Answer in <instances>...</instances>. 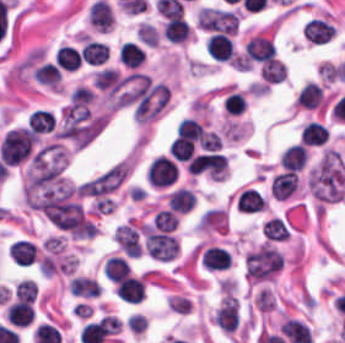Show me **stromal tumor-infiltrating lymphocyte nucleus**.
<instances>
[{
  "label": "stromal tumor-infiltrating lymphocyte nucleus",
  "mask_w": 345,
  "mask_h": 343,
  "mask_svg": "<svg viewBox=\"0 0 345 343\" xmlns=\"http://www.w3.org/2000/svg\"><path fill=\"white\" fill-rule=\"evenodd\" d=\"M146 176L152 187H166L176 181L178 170L173 160L159 155L149 165Z\"/></svg>",
  "instance_id": "obj_1"
},
{
  "label": "stromal tumor-infiltrating lymphocyte nucleus",
  "mask_w": 345,
  "mask_h": 343,
  "mask_svg": "<svg viewBox=\"0 0 345 343\" xmlns=\"http://www.w3.org/2000/svg\"><path fill=\"white\" fill-rule=\"evenodd\" d=\"M245 59L265 62L274 57L273 41L264 36H251L243 50Z\"/></svg>",
  "instance_id": "obj_2"
},
{
  "label": "stromal tumor-infiltrating lymphocyte nucleus",
  "mask_w": 345,
  "mask_h": 343,
  "mask_svg": "<svg viewBox=\"0 0 345 343\" xmlns=\"http://www.w3.org/2000/svg\"><path fill=\"white\" fill-rule=\"evenodd\" d=\"M205 48L208 54L218 61H226L235 55L231 38L220 32L209 34L205 42Z\"/></svg>",
  "instance_id": "obj_3"
},
{
  "label": "stromal tumor-infiltrating lymphocyte nucleus",
  "mask_w": 345,
  "mask_h": 343,
  "mask_svg": "<svg viewBox=\"0 0 345 343\" xmlns=\"http://www.w3.org/2000/svg\"><path fill=\"white\" fill-rule=\"evenodd\" d=\"M114 292L121 301L139 303L144 298V283L142 279L128 274L116 282Z\"/></svg>",
  "instance_id": "obj_4"
},
{
  "label": "stromal tumor-infiltrating lymphocyte nucleus",
  "mask_w": 345,
  "mask_h": 343,
  "mask_svg": "<svg viewBox=\"0 0 345 343\" xmlns=\"http://www.w3.org/2000/svg\"><path fill=\"white\" fill-rule=\"evenodd\" d=\"M302 31L308 41L319 44L333 37L335 26L318 17H311L306 21Z\"/></svg>",
  "instance_id": "obj_5"
},
{
  "label": "stromal tumor-infiltrating lymphocyte nucleus",
  "mask_w": 345,
  "mask_h": 343,
  "mask_svg": "<svg viewBox=\"0 0 345 343\" xmlns=\"http://www.w3.org/2000/svg\"><path fill=\"white\" fill-rule=\"evenodd\" d=\"M5 314L7 320L16 327H26L34 318L31 304L25 301L10 302Z\"/></svg>",
  "instance_id": "obj_6"
},
{
  "label": "stromal tumor-infiltrating lymphocyte nucleus",
  "mask_w": 345,
  "mask_h": 343,
  "mask_svg": "<svg viewBox=\"0 0 345 343\" xmlns=\"http://www.w3.org/2000/svg\"><path fill=\"white\" fill-rule=\"evenodd\" d=\"M202 264L209 270H222L230 267L231 254L226 248L208 246L202 255Z\"/></svg>",
  "instance_id": "obj_7"
},
{
  "label": "stromal tumor-infiltrating lymphocyte nucleus",
  "mask_w": 345,
  "mask_h": 343,
  "mask_svg": "<svg viewBox=\"0 0 345 343\" xmlns=\"http://www.w3.org/2000/svg\"><path fill=\"white\" fill-rule=\"evenodd\" d=\"M327 126L317 119H310L302 128L300 137L302 144L322 145L328 138Z\"/></svg>",
  "instance_id": "obj_8"
},
{
  "label": "stromal tumor-infiltrating lymphocyte nucleus",
  "mask_w": 345,
  "mask_h": 343,
  "mask_svg": "<svg viewBox=\"0 0 345 343\" xmlns=\"http://www.w3.org/2000/svg\"><path fill=\"white\" fill-rule=\"evenodd\" d=\"M322 102L321 85L312 81H305L298 94L295 97L294 103L301 108H314L319 106Z\"/></svg>",
  "instance_id": "obj_9"
},
{
  "label": "stromal tumor-infiltrating lymphocyte nucleus",
  "mask_w": 345,
  "mask_h": 343,
  "mask_svg": "<svg viewBox=\"0 0 345 343\" xmlns=\"http://www.w3.org/2000/svg\"><path fill=\"white\" fill-rule=\"evenodd\" d=\"M92 80L98 90L113 93L119 90L124 79L118 70L107 67L94 73Z\"/></svg>",
  "instance_id": "obj_10"
},
{
  "label": "stromal tumor-infiltrating lymphocyte nucleus",
  "mask_w": 345,
  "mask_h": 343,
  "mask_svg": "<svg viewBox=\"0 0 345 343\" xmlns=\"http://www.w3.org/2000/svg\"><path fill=\"white\" fill-rule=\"evenodd\" d=\"M81 59L90 65H101L108 57L106 43L87 40L80 49Z\"/></svg>",
  "instance_id": "obj_11"
},
{
  "label": "stromal tumor-infiltrating lymphocyte nucleus",
  "mask_w": 345,
  "mask_h": 343,
  "mask_svg": "<svg viewBox=\"0 0 345 343\" xmlns=\"http://www.w3.org/2000/svg\"><path fill=\"white\" fill-rule=\"evenodd\" d=\"M8 254L17 264H31L36 256V248L25 239H17L10 242Z\"/></svg>",
  "instance_id": "obj_12"
},
{
  "label": "stromal tumor-infiltrating lymphocyte nucleus",
  "mask_w": 345,
  "mask_h": 343,
  "mask_svg": "<svg viewBox=\"0 0 345 343\" xmlns=\"http://www.w3.org/2000/svg\"><path fill=\"white\" fill-rule=\"evenodd\" d=\"M55 64L59 69L76 70L81 65L79 51L69 44H62L54 55Z\"/></svg>",
  "instance_id": "obj_13"
},
{
  "label": "stromal tumor-infiltrating lymphocyte nucleus",
  "mask_w": 345,
  "mask_h": 343,
  "mask_svg": "<svg viewBox=\"0 0 345 343\" xmlns=\"http://www.w3.org/2000/svg\"><path fill=\"white\" fill-rule=\"evenodd\" d=\"M305 158V145L301 143H294L284 150V152L280 156L279 163L280 166L286 167L291 170H301Z\"/></svg>",
  "instance_id": "obj_14"
},
{
  "label": "stromal tumor-infiltrating lymphocyte nucleus",
  "mask_w": 345,
  "mask_h": 343,
  "mask_svg": "<svg viewBox=\"0 0 345 343\" xmlns=\"http://www.w3.org/2000/svg\"><path fill=\"white\" fill-rule=\"evenodd\" d=\"M190 30L182 17H168L162 36L171 42H184Z\"/></svg>",
  "instance_id": "obj_15"
},
{
  "label": "stromal tumor-infiltrating lymphocyte nucleus",
  "mask_w": 345,
  "mask_h": 343,
  "mask_svg": "<svg viewBox=\"0 0 345 343\" xmlns=\"http://www.w3.org/2000/svg\"><path fill=\"white\" fill-rule=\"evenodd\" d=\"M194 201L189 188L176 187L166 198V205L178 213H187Z\"/></svg>",
  "instance_id": "obj_16"
},
{
  "label": "stromal tumor-infiltrating lymphocyte nucleus",
  "mask_w": 345,
  "mask_h": 343,
  "mask_svg": "<svg viewBox=\"0 0 345 343\" xmlns=\"http://www.w3.org/2000/svg\"><path fill=\"white\" fill-rule=\"evenodd\" d=\"M32 79L38 84L57 87L60 81L59 68L50 62H43L33 68Z\"/></svg>",
  "instance_id": "obj_17"
},
{
  "label": "stromal tumor-infiltrating lymphocyte nucleus",
  "mask_w": 345,
  "mask_h": 343,
  "mask_svg": "<svg viewBox=\"0 0 345 343\" xmlns=\"http://www.w3.org/2000/svg\"><path fill=\"white\" fill-rule=\"evenodd\" d=\"M285 74V64L275 58H268L259 69V76L265 84H276Z\"/></svg>",
  "instance_id": "obj_18"
},
{
  "label": "stromal tumor-infiltrating lymphocyte nucleus",
  "mask_w": 345,
  "mask_h": 343,
  "mask_svg": "<svg viewBox=\"0 0 345 343\" xmlns=\"http://www.w3.org/2000/svg\"><path fill=\"white\" fill-rule=\"evenodd\" d=\"M108 281L116 282L129 273V266L124 257L111 255L102 268Z\"/></svg>",
  "instance_id": "obj_19"
},
{
  "label": "stromal tumor-infiltrating lymphocyte nucleus",
  "mask_w": 345,
  "mask_h": 343,
  "mask_svg": "<svg viewBox=\"0 0 345 343\" xmlns=\"http://www.w3.org/2000/svg\"><path fill=\"white\" fill-rule=\"evenodd\" d=\"M122 63L128 68H136L145 58L144 49L133 41H125L118 53Z\"/></svg>",
  "instance_id": "obj_20"
},
{
  "label": "stromal tumor-infiltrating lymphocyte nucleus",
  "mask_w": 345,
  "mask_h": 343,
  "mask_svg": "<svg viewBox=\"0 0 345 343\" xmlns=\"http://www.w3.org/2000/svg\"><path fill=\"white\" fill-rule=\"evenodd\" d=\"M27 125L35 132L42 133L54 128V119L47 110L35 109L27 117Z\"/></svg>",
  "instance_id": "obj_21"
},
{
  "label": "stromal tumor-infiltrating lymphocyte nucleus",
  "mask_w": 345,
  "mask_h": 343,
  "mask_svg": "<svg viewBox=\"0 0 345 343\" xmlns=\"http://www.w3.org/2000/svg\"><path fill=\"white\" fill-rule=\"evenodd\" d=\"M155 230L173 231L178 224V216L169 209H162L152 216Z\"/></svg>",
  "instance_id": "obj_22"
},
{
  "label": "stromal tumor-infiltrating lymphocyte nucleus",
  "mask_w": 345,
  "mask_h": 343,
  "mask_svg": "<svg viewBox=\"0 0 345 343\" xmlns=\"http://www.w3.org/2000/svg\"><path fill=\"white\" fill-rule=\"evenodd\" d=\"M37 295V286L29 279H22L15 285L14 296L19 301H33Z\"/></svg>",
  "instance_id": "obj_23"
},
{
  "label": "stromal tumor-infiltrating lymphocyte nucleus",
  "mask_w": 345,
  "mask_h": 343,
  "mask_svg": "<svg viewBox=\"0 0 345 343\" xmlns=\"http://www.w3.org/2000/svg\"><path fill=\"white\" fill-rule=\"evenodd\" d=\"M247 107V102L241 91H232L225 97L224 108L232 114L242 113Z\"/></svg>",
  "instance_id": "obj_24"
},
{
  "label": "stromal tumor-infiltrating lymphocyte nucleus",
  "mask_w": 345,
  "mask_h": 343,
  "mask_svg": "<svg viewBox=\"0 0 345 343\" xmlns=\"http://www.w3.org/2000/svg\"><path fill=\"white\" fill-rule=\"evenodd\" d=\"M70 101L74 106H87L90 104L95 95L91 89L86 86H78L69 94Z\"/></svg>",
  "instance_id": "obj_25"
},
{
  "label": "stromal tumor-infiltrating lymphocyte nucleus",
  "mask_w": 345,
  "mask_h": 343,
  "mask_svg": "<svg viewBox=\"0 0 345 343\" xmlns=\"http://www.w3.org/2000/svg\"><path fill=\"white\" fill-rule=\"evenodd\" d=\"M135 34L139 41L148 45H156L158 42V31L156 27L147 22L141 21Z\"/></svg>",
  "instance_id": "obj_26"
}]
</instances>
